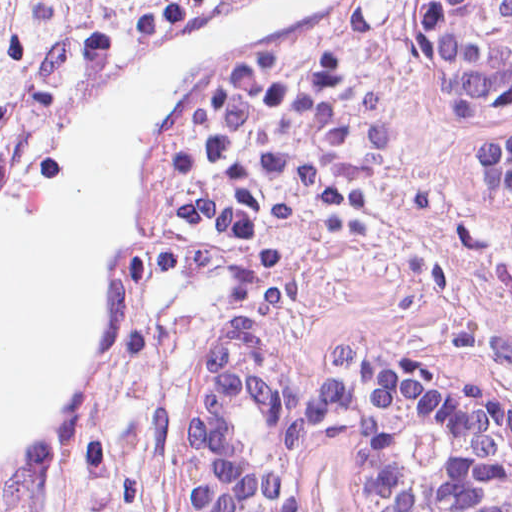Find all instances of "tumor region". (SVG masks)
Returning a JSON list of instances; mask_svg holds the SVG:
<instances>
[{
  "label": "tumor region",
  "mask_w": 512,
  "mask_h": 512,
  "mask_svg": "<svg viewBox=\"0 0 512 512\" xmlns=\"http://www.w3.org/2000/svg\"><path fill=\"white\" fill-rule=\"evenodd\" d=\"M229 1L0 0V176L117 62ZM401 1L406 10L408 92L418 123L467 128L476 143L487 132H512V121L447 116L420 96L412 69L413 0ZM283 52L328 53L311 46L300 34L274 53ZM208 89L178 118L135 196L129 249L108 284V346L96 396L100 430L95 432L87 417L47 453L2 476L0 512H170L168 447L181 388L198 352L223 334L162 322L149 310L142 293L163 255L166 170L172 143L188 110ZM475 180L487 196H509ZM324 233L276 265L263 281L242 328L254 331L301 376L314 375L324 353L312 355L298 349L282 309V283L294 260ZM374 343L394 344L456 364L483 376L512 398L510 385L482 373L437 341L392 338ZM94 443L109 460L116 479L88 472L86 453ZM326 497L349 501L348 471L332 426H321L313 433L301 461L291 512H317Z\"/></svg>",
  "instance_id": "tumor-region-1"
}]
</instances>
